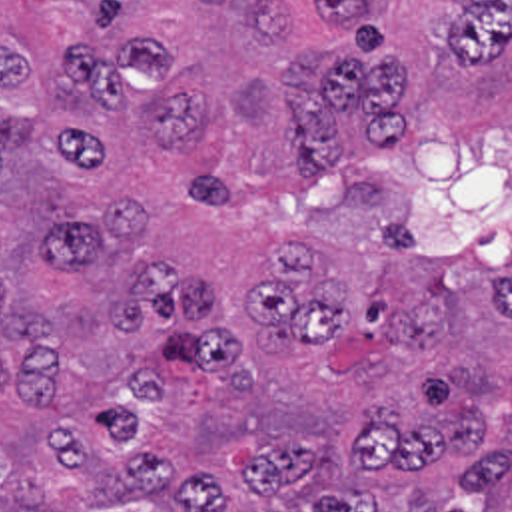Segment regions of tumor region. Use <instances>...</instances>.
I'll return each mask as SVG.
<instances>
[{"label":"tumor region","instance_id":"1","mask_svg":"<svg viewBox=\"0 0 512 512\" xmlns=\"http://www.w3.org/2000/svg\"><path fill=\"white\" fill-rule=\"evenodd\" d=\"M404 94L372 0H0V512H512V118Z\"/></svg>","mask_w":512,"mask_h":512}]
</instances>
